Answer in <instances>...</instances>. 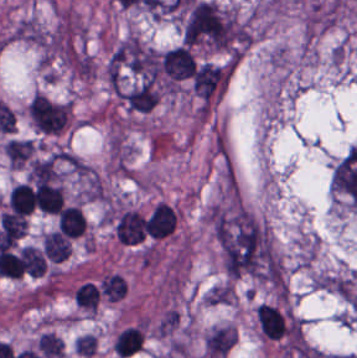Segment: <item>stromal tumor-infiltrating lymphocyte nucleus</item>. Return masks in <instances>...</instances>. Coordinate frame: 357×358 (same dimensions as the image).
Masks as SVG:
<instances>
[{"label": "stromal tumor-infiltrating lymphocyte nucleus", "instance_id": "14", "mask_svg": "<svg viewBox=\"0 0 357 358\" xmlns=\"http://www.w3.org/2000/svg\"><path fill=\"white\" fill-rule=\"evenodd\" d=\"M97 345L96 336L89 333L78 335L74 339V351L79 354L91 355L93 354Z\"/></svg>", "mask_w": 357, "mask_h": 358}, {"label": "stromal tumor-infiltrating lymphocyte nucleus", "instance_id": "5", "mask_svg": "<svg viewBox=\"0 0 357 358\" xmlns=\"http://www.w3.org/2000/svg\"><path fill=\"white\" fill-rule=\"evenodd\" d=\"M143 227L142 213L130 208L119 217L114 233L119 242L134 244L143 237Z\"/></svg>", "mask_w": 357, "mask_h": 358}, {"label": "stromal tumor-infiltrating lymphocyte nucleus", "instance_id": "4", "mask_svg": "<svg viewBox=\"0 0 357 358\" xmlns=\"http://www.w3.org/2000/svg\"><path fill=\"white\" fill-rule=\"evenodd\" d=\"M159 93L160 89L157 84L138 81L125 88L121 97L127 109L142 113L154 108Z\"/></svg>", "mask_w": 357, "mask_h": 358}, {"label": "stromal tumor-infiltrating lymphocyte nucleus", "instance_id": "3", "mask_svg": "<svg viewBox=\"0 0 357 358\" xmlns=\"http://www.w3.org/2000/svg\"><path fill=\"white\" fill-rule=\"evenodd\" d=\"M161 65L168 78L177 80L188 77L196 67L189 46L185 45H178L164 52Z\"/></svg>", "mask_w": 357, "mask_h": 358}, {"label": "stromal tumor-infiltrating lymphocyte nucleus", "instance_id": "7", "mask_svg": "<svg viewBox=\"0 0 357 358\" xmlns=\"http://www.w3.org/2000/svg\"><path fill=\"white\" fill-rule=\"evenodd\" d=\"M58 228L66 237H80L86 220L79 205H65L58 212Z\"/></svg>", "mask_w": 357, "mask_h": 358}, {"label": "stromal tumor-infiltrating lymphocyte nucleus", "instance_id": "8", "mask_svg": "<svg viewBox=\"0 0 357 358\" xmlns=\"http://www.w3.org/2000/svg\"><path fill=\"white\" fill-rule=\"evenodd\" d=\"M42 249L50 261L61 263L71 250V242L66 236L53 229L42 236Z\"/></svg>", "mask_w": 357, "mask_h": 358}, {"label": "stromal tumor-infiltrating lymphocyte nucleus", "instance_id": "9", "mask_svg": "<svg viewBox=\"0 0 357 358\" xmlns=\"http://www.w3.org/2000/svg\"><path fill=\"white\" fill-rule=\"evenodd\" d=\"M143 341L142 329L139 326H126L120 331L112 345L116 354L125 356L140 347Z\"/></svg>", "mask_w": 357, "mask_h": 358}, {"label": "stromal tumor-infiltrating lymphocyte nucleus", "instance_id": "2", "mask_svg": "<svg viewBox=\"0 0 357 358\" xmlns=\"http://www.w3.org/2000/svg\"><path fill=\"white\" fill-rule=\"evenodd\" d=\"M178 224V212L174 205L158 201L146 217L144 233L146 239L157 241L172 235Z\"/></svg>", "mask_w": 357, "mask_h": 358}, {"label": "stromal tumor-infiltrating lymphocyte nucleus", "instance_id": "12", "mask_svg": "<svg viewBox=\"0 0 357 358\" xmlns=\"http://www.w3.org/2000/svg\"><path fill=\"white\" fill-rule=\"evenodd\" d=\"M99 290L90 281H83L77 288L74 297L77 303L89 310L95 311L99 300Z\"/></svg>", "mask_w": 357, "mask_h": 358}, {"label": "stromal tumor-infiltrating lymphocyte nucleus", "instance_id": "10", "mask_svg": "<svg viewBox=\"0 0 357 358\" xmlns=\"http://www.w3.org/2000/svg\"><path fill=\"white\" fill-rule=\"evenodd\" d=\"M99 288L105 299L116 301L126 293V280L120 273L111 272L101 278Z\"/></svg>", "mask_w": 357, "mask_h": 358}, {"label": "stromal tumor-infiltrating lymphocyte nucleus", "instance_id": "1", "mask_svg": "<svg viewBox=\"0 0 357 358\" xmlns=\"http://www.w3.org/2000/svg\"><path fill=\"white\" fill-rule=\"evenodd\" d=\"M230 66L203 63L194 74L193 90L206 109L223 92Z\"/></svg>", "mask_w": 357, "mask_h": 358}, {"label": "stromal tumor-infiltrating lymphocyte nucleus", "instance_id": "11", "mask_svg": "<svg viewBox=\"0 0 357 358\" xmlns=\"http://www.w3.org/2000/svg\"><path fill=\"white\" fill-rule=\"evenodd\" d=\"M19 251L22 263L28 274L41 276L46 271L44 256L39 248L29 244L19 248Z\"/></svg>", "mask_w": 357, "mask_h": 358}, {"label": "stromal tumor-infiltrating lymphocyte nucleus", "instance_id": "13", "mask_svg": "<svg viewBox=\"0 0 357 358\" xmlns=\"http://www.w3.org/2000/svg\"><path fill=\"white\" fill-rule=\"evenodd\" d=\"M42 356L61 357L64 344L53 333L44 332L37 341Z\"/></svg>", "mask_w": 357, "mask_h": 358}, {"label": "stromal tumor-infiltrating lymphocyte nucleus", "instance_id": "6", "mask_svg": "<svg viewBox=\"0 0 357 358\" xmlns=\"http://www.w3.org/2000/svg\"><path fill=\"white\" fill-rule=\"evenodd\" d=\"M256 319L265 336L278 337L289 330L281 312L263 301L256 309Z\"/></svg>", "mask_w": 357, "mask_h": 358}]
</instances>
